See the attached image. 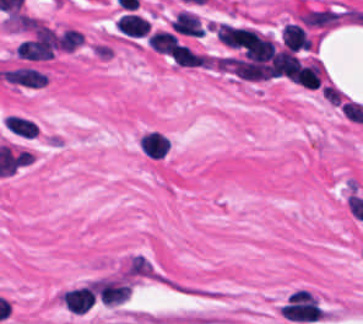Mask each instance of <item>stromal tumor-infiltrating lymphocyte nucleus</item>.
<instances>
[{
  "label": "stromal tumor-infiltrating lymphocyte nucleus",
  "mask_w": 363,
  "mask_h": 324,
  "mask_svg": "<svg viewBox=\"0 0 363 324\" xmlns=\"http://www.w3.org/2000/svg\"><path fill=\"white\" fill-rule=\"evenodd\" d=\"M7 81L28 88H38L46 79L44 72L30 66H17L0 71Z\"/></svg>",
  "instance_id": "obj_1"
},
{
  "label": "stromal tumor-infiltrating lymphocyte nucleus",
  "mask_w": 363,
  "mask_h": 324,
  "mask_svg": "<svg viewBox=\"0 0 363 324\" xmlns=\"http://www.w3.org/2000/svg\"><path fill=\"white\" fill-rule=\"evenodd\" d=\"M322 65L316 59L300 61L291 74L292 81L306 88H316L322 73Z\"/></svg>",
  "instance_id": "obj_2"
},
{
  "label": "stromal tumor-infiltrating lymphocyte nucleus",
  "mask_w": 363,
  "mask_h": 324,
  "mask_svg": "<svg viewBox=\"0 0 363 324\" xmlns=\"http://www.w3.org/2000/svg\"><path fill=\"white\" fill-rule=\"evenodd\" d=\"M280 38L285 46L295 52L310 46L304 28L298 23H285L281 29Z\"/></svg>",
  "instance_id": "obj_3"
},
{
  "label": "stromal tumor-infiltrating lymphocyte nucleus",
  "mask_w": 363,
  "mask_h": 324,
  "mask_svg": "<svg viewBox=\"0 0 363 324\" xmlns=\"http://www.w3.org/2000/svg\"><path fill=\"white\" fill-rule=\"evenodd\" d=\"M139 145L145 154L162 157L165 155L170 143L167 136L159 130L153 129L142 133Z\"/></svg>",
  "instance_id": "obj_4"
},
{
  "label": "stromal tumor-infiltrating lymphocyte nucleus",
  "mask_w": 363,
  "mask_h": 324,
  "mask_svg": "<svg viewBox=\"0 0 363 324\" xmlns=\"http://www.w3.org/2000/svg\"><path fill=\"white\" fill-rule=\"evenodd\" d=\"M115 25L119 32L126 35L142 36L146 35L149 25L141 15L125 12L115 20Z\"/></svg>",
  "instance_id": "obj_5"
},
{
  "label": "stromal tumor-infiltrating lymphocyte nucleus",
  "mask_w": 363,
  "mask_h": 324,
  "mask_svg": "<svg viewBox=\"0 0 363 324\" xmlns=\"http://www.w3.org/2000/svg\"><path fill=\"white\" fill-rule=\"evenodd\" d=\"M146 42L148 48H150L151 50L169 56L180 44L175 33L168 32L162 29H155L150 32Z\"/></svg>",
  "instance_id": "obj_6"
},
{
  "label": "stromal tumor-infiltrating lymphocyte nucleus",
  "mask_w": 363,
  "mask_h": 324,
  "mask_svg": "<svg viewBox=\"0 0 363 324\" xmlns=\"http://www.w3.org/2000/svg\"><path fill=\"white\" fill-rule=\"evenodd\" d=\"M6 130L13 136L32 138L35 132V121L25 115L8 113L4 119Z\"/></svg>",
  "instance_id": "obj_7"
},
{
  "label": "stromal tumor-infiltrating lymphocyte nucleus",
  "mask_w": 363,
  "mask_h": 324,
  "mask_svg": "<svg viewBox=\"0 0 363 324\" xmlns=\"http://www.w3.org/2000/svg\"><path fill=\"white\" fill-rule=\"evenodd\" d=\"M174 30L180 34L202 35L195 12L179 10L173 20Z\"/></svg>",
  "instance_id": "obj_8"
},
{
  "label": "stromal tumor-infiltrating lymphocyte nucleus",
  "mask_w": 363,
  "mask_h": 324,
  "mask_svg": "<svg viewBox=\"0 0 363 324\" xmlns=\"http://www.w3.org/2000/svg\"><path fill=\"white\" fill-rule=\"evenodd\" d=\"M171 56L178 66L207 67V59L202 54L192 50L191 48L181 43L176 47Z\"/></svg>",
  "instance_id": "obj_9"
}]
</instances>
